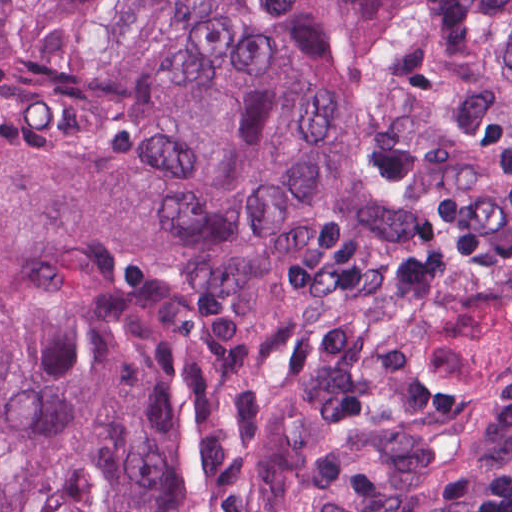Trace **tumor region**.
Here are the masks:
<instances>
[{"label": "tumor region", "instance_id": "tumor-region-1", "mask_svg": "<svg viewBox=\"0 0 512 512\" xmlns=\"http://www.w3.org/2000/svg\"><path fill=\"white\" fill-rule=\"evenodd\" d=\"M512 338V0H0V512H343Z\"/></svg>", "mask_w": 512, "mask_h": 512}]
</instances>
